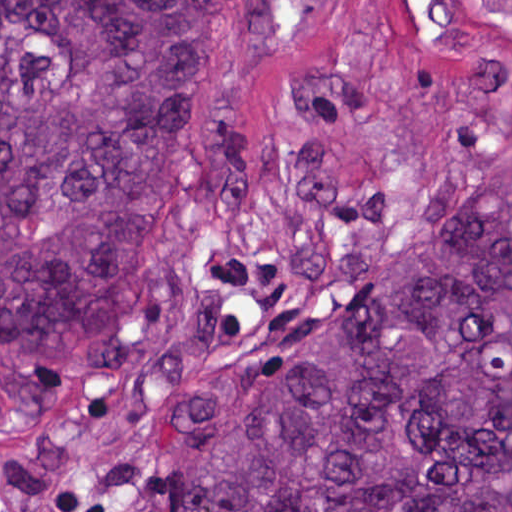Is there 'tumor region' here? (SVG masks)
I'll use <instances>...</instances> for the list:
<instances>
[{"mask_svg":"<svg viewBox=\"0 0 512 512\" xmlns=\"http://www.w3.org/2000/svg\"><path fill=\"white\" fill-rule=\"evenodd\" d=\"M268 34L269 0H0V351L121 334L135 261L244 134ZM220 412L160 512H512V171Z\"/></svg>","mask_w":512,"mask_h":512,"instance_id":"e687c5a6","label":"tumor region"}]
</instances>
